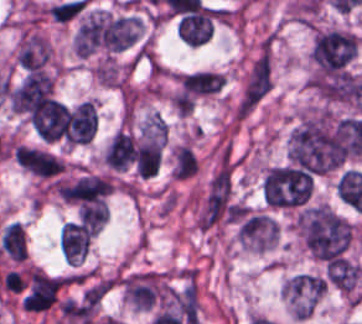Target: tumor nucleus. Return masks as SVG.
Segmentation results:
<instances>
[{
    "mask_svg": "<svg viewBox=\"0 0 362 324\" xmlns=\"http://www.w3.org/2000/svg\"><path fill=\"white\" fill-rule=\"evenodd\" d=\"M362 153L300 113L288 137L293 165L309 174L337 171Z\"/></svg>",
    "mask_w": 362,
    "mask_h": 324,
    "instance_id": "obj_1",
    "label": "tumor nucleus"
},
{
    "mask_svg": "<svg viewBox=\"0 0 362 324\" xmlns=\"http://www.w3.org/2000/svg\"><path fill=\"white\" fill-rule=\"evenodd\" d=\"M295 221L306 253L321 262L340 258L350 243L348 222L325 206H305Z\"/></svg>",
    "mask_w": 362,
    "mask_h": 324,
    "instance_id": "obj_2",
    "label": "tumor nucleus"
},
{
    "mask_svg": "<svg viewBox=\"0 0 362 324\" xmlns=\"http://www.w3.org/2000/svg\"><path fill=\"white\" fill-rule=\"evenodd\" d=\"M239 203L231 171H217L197 206L200 231H213L238 219Z\"/></svg>",
    "mask_w": 362,
    "mask_h": 324,
    "instance_id": "obj_3",
    "label": "tumor nucleus"
},
{
    "mask_svg": "<svg viewBox=\"0 0 362 324\" xmlns=\"http://www.w3.org/2000/svg\"><path fill=\"white\" fill-rule=\"evenodd\" d=\"M312 179L308 173L288 163L270 167L261 183L264 205L275 209L301 206L308 200Z\"/></svg>",
    "mask_w": 362,
    "mask_h": 324,
    "instance_id": "obj_4",
    "label": "tumor nucleus"
},
{
    "mask_svg": "<svg viewBox=\"0 0 362 324\" xmlns=\"http://www.w3.org/2000/svg\"><path fill=\"white\" fill-rule=\"evenodd\" d=\"M123 297L135 309L156 310L169 296V281L159 270H129L121 279Z\"/></svg>",
    "mask_w": 362,
    "mask_h": 324,
    "instance_id": "obj_5",
    "label": "tumor nucleus"
},
{
    "mask_svg": "<svg viewBox=\"0 0 362 324\" xmlns=\"http://www.w3.org/2000/svg\"><path fill=\"white\" fill-rule=\"evenodd\" d=\"M278 226L266 212L247 209L236 223L238 244L252 252H265L276 244Z\"/></svg>",
    "mask_w": 362,
    "mask_h": 324,
    "instance_id": "obj_6",
    "label": "tumor nucleus"
},
{
    "mask_svg": "<svg viewBox=\"0 0 362 324\" xmlns=\"http://www.w3.org/2000/svg\"><path fill=\"white\" fill-rule=\"evenodd\" d=\"M63 275L29 268L26 273L21 306L27 311H43L66 285Z\"/></svg>",
    "mask_w": 362,
    "mask_h": 324,
    "instance_id": "obj_7",
    "label": "tumor nucleus"
},
{
    "mask_svg": "<svg viewBox=\"0 0 362 324\" xmlns=\"http://www.w3.org/2000/svg\"><path fill=\"white\" fill-rule=\"evenodd\" d=\"M111 190L107 176L86 174L55 182L58 197L67 202L94 203L106 197Z\"/></svg>",
    "mask_w": 362,
    "mask_h": 324,
    "instance_id": "obj_8",
    "label": "tumor nucleus"
},
{
    "mask_svg": "<svg viewBox=\"0 0 362 324\" xmlns=\"http://www.w3.org/2000/svg\"><path fill=\"white\" fill-rule=\"evenodd\" d=\"M15 157L21 169L40 180H54L66 171L63 160L51 150L20 144Z\"/></svg>",
    "mask_w": 362,
    "mask_h": 324,
    "instance_id": "obj_9",
    "label": "tumor nucleus"
},
{
    "mask_svg": "<svg viewBox=\"0 0 362 324\" xmlns=\"http://www.w3.org/2000/svg\"><path fill=\"white\" fill-rule=\"evenodd\" d=\"M96 128L95 103L84 99L68 112L63 136L67 144H80L89 141Z\"/></svg>",
    "mask_w": 362,
    "mask_h": 324,
    "instance_id": "obj_10",
    "label": "tumor nucleus"
},
{
    "mask_svg": "<svg viewBox=\"0 0 362 324\" xmlns=\"http://www.w3.org/2000/svg\"><path fill=\"white\" fill-rule=\"evenodd\" d=\"M271 86V59L268 53H260L249 63L243 78L239 100L257 103Z\"/></svg>",
    "mask_w": 362,
    "mask_h": 324,
    "instance_id": "obj_11",
    "label": "tumor nucleus"
},
{
    "mask_svg": "<svg viewBox=\"0 0 362 324\" xmlns=\"http://www.w3.org/2000/svg\"><path fill=\"white\" fill-rule=\"evenodd\" d=\"M51 49L45 38L36 32L22 31L17 41L16 59L27 70L43 66Z\"/></svg>",
    "mask_w": 362,
    "mask_h": 324,
    "instance_id": "obj_12",
    "label": "tumor nucleus"
},
{
    "mask_svg": "<svg viewBox=\"0 0 362 324\" xmlns=\"http://www.w3.org/2000/svg\"><path fill=\"white\" fill-rule=\"evenodd\" d=\"M135 154V141L132 136L117 130L104 149V161L112 169H125Z\"/></svg>",
    "mask_w": 362,
    "mask_h": 324,
    "instance_id": "obj_13",
    "label": "tumor nucleus"
},
{
    "mask_svg": "<svg viewBox=\"0 0 362 324\" xmlns=\"http://www.w3.org/2000/svg\"><path fill=\"white\" fill-rule=\"evenodd\" d=\"M3 253L13 262H23L27 257L26 236L20 222L5 226L0 235Z\"/></svg>",
    "mask_w": 362,
    "mask_h": 324,
    "instance_id": "obj_14",
    "label": "tumor nucleus"
},
{
    "mask_svg": "<svg viewBox=\"0 0 362 324\" xmlns=\"http://www.w3.org/2000/svg\"><path fill=\"white\" fill-rule=\"evenodd\" d=\"M161 144L138 141L135 144V167L139 177H151L159 170Z\"/></svg>",
    "mask_w": 362,
    "mask_h": 324,
    "instance_id": "obj_15",
    "label": "tumor nucleus"
},
{
    "mask_svg": "<svg viewBox=\"0 0 362 324\" xmlns=\"http://www.w3.org/2000/svg\"><path fill=\"white\" fill-rule=\"evenodd\" d=\"M198 160L188 145L176 144L171 149L170 174L176 180H185L196 174Z\"/></svg>",
    "mask_w": 362,
    "mask_h": 324,
    "instance_id": "obj_16",
    "label": "tumor nucleus"
},
{
    "mask_svg": "<svg viewBox=\"0 0 362 324\" xmlns=\"http://www.w3.org/2000/svg\"><path fill=\"white\" fill-rule=\"evenodd\" d=\"M108 210L102 201H95L78 208L79 221L88 227L101 228L106 217Z\"/></svg>",
    "mask_w": 362,
    "mask_h": 324,
    "instance_id": "obj_17",
    "label": "tumor nucleus"
}]
</instances>
